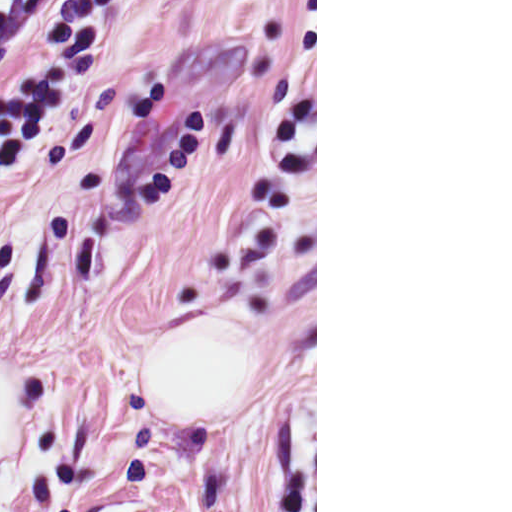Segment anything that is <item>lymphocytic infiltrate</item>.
<instances>
[{
  "label": "lymphocytic infiltrate",
  "instance_id": "1",
  "mask_svg": "<svg viewBox=\"0 0 512 512\" xmlns=\"http://www.w3.org/2000/svg\"><path fill=\"white\" fill-rule=\"evenodd\" d=\"M40 0H0V23L20 15Z\"/></svg>",
  "mask_w": 512,
  "mask_h": 512
}]
</instances>
